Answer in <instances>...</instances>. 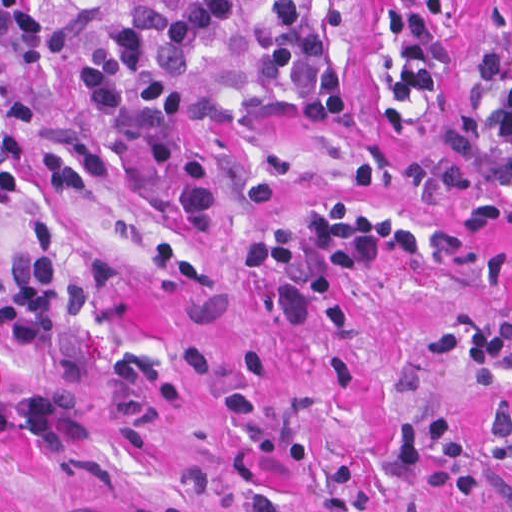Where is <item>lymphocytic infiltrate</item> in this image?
I'll list each match as a JSON object with an SVG mask.
<instances>
[{
  "label": "lymphocytic infiltrate",
  "instance_id": "obj_1",
  "mask_svg": "<svg viewBox=\"0 0 512 512\" xmlns=\"http://www.w3.org/2000/svg\"><path fill=\"white\" fill-rule=\"evenodd\" d=\"M64 0H1V53L14 82L26 81L64 50L63 31L45 30L33 6ZM350 0H132L91 36L87 71L45 116L38 172L117 168L150 151L160 124L180 111L197 84L204 45L238 50L244 71L203 106L193 140L167 174L163 196L182 200L226 177L275 133L328 139L350 107L352 67L344 46ZM468 0H371L369 115L391 141L415 130L437 101L467 18ZM357 183L400 190L438 209L470 203L463 244L490 225L512 223V0H490L488 45L465 77L457 158L404 165L365 164ZM425 249V236L398 215L364 210L334 195L304 239L271 236L254 250L260 269L282 263L315 296L329 331L349 328L341 285L374 259ZM63 313L50 225L33 222L24 262L1 290V346L28 360L27 431L41 443L79 435V401L58 386ZM423 351L440 364L496 370L512 356V319L463 325L430 337ZM485 434L504 475L512 477V404L497 403ZM440 460L428 475L437 499L475 500V461L445 413L408 416L392 436L408 472Z\"/></svg>",
  "mask_w": 512,
  "mask_h": 512
}]
</instances>
